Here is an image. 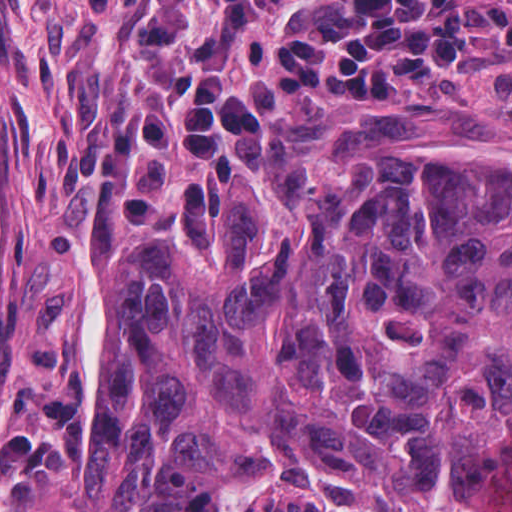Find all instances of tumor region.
Masks as SVG:
<instances>
[{
	"mask_svg": "<svg viewBox=\"0 0 512 512\" xmlns=\"http://www.w3.org/2000/svg\"><path fill=\"white\" fill-rule=\"evenodd\" d=\"M360 134L119 246L69 512H512V150Z\"/></svg>",
	"mask_w": 512,
	"mask_h": 512,
	"instance_id": "obj_1",
	"label": "tumor region"
}]
</instances>
